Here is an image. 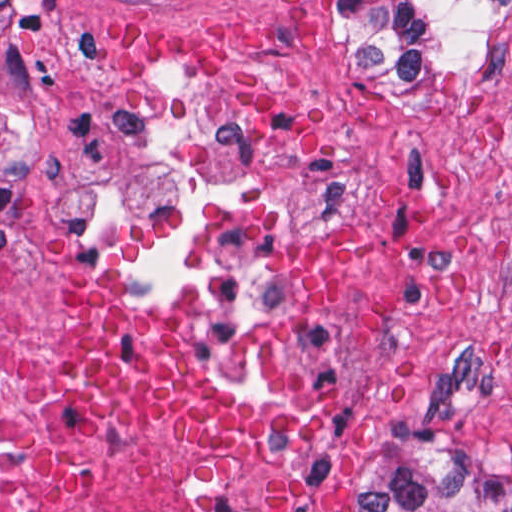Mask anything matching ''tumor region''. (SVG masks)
I'll list each match as a JSON object with an SVG mask.
<instances>
[{"label": "tumor region", "instance_id": "tumor-region-1", "mask_svg": "<svg viewBox=\"0 0 512 512\" xmlns=\"http://www.w3.org/2000/svg\"><path fill=\"white\" fill-rule=\"evenodd\" d=\"M398 63L420 69L491 20L510 0H330ZM365 512H512V450L453 466L435 411L408 416L392 482Z\"/></svg>", "mask_w": 512, "mask_h": 512}]
</instances>
